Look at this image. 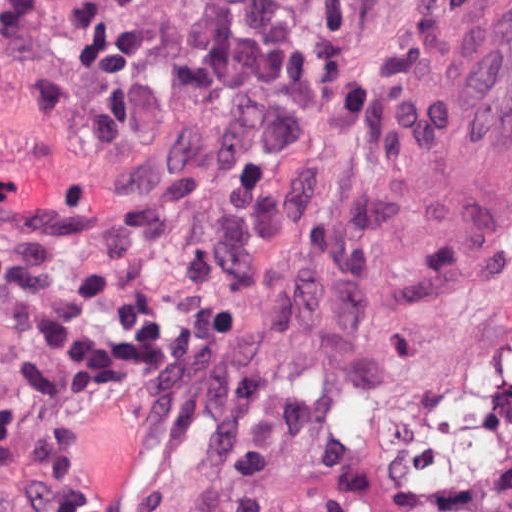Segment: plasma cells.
Instances as JSON below:
<instances>
[{"label":"plasma cells","instance_id":"9512152a","mask_svg":"<svg viewBox=\"0 0 512 512\" xmlns=\"http://www.w3.org/2000/svg\"><path fill=\"white\" fill-rule=\"evenodd\" d=\"M339 11L355 0H314ZM190 43L169 57L166 81L193 108L241 93L307 106L321 93L324 58L280 0H186ZM65 38L82 85L35 82L31 92L80 140L89 164L133 139L156 100L158 28L152 0H84ZM94 481L73 441V404L28 408L0 433V512H93Z\"/></svg>","mask_w":512,"mask_h":512}]
</instances>
